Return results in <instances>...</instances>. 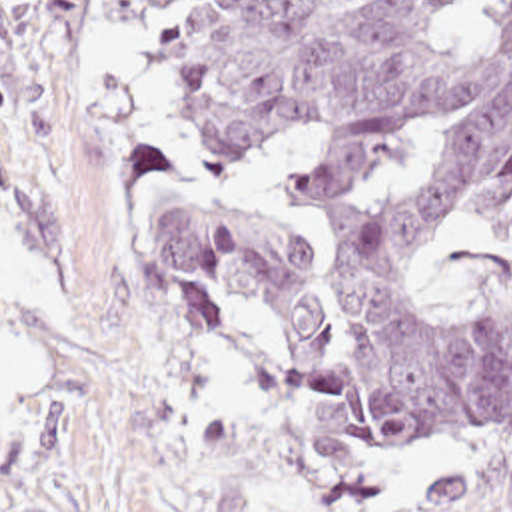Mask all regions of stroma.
<instances>
[{
	"label": "stroma",
	"instance_id": "obj_1",
	"mask_svg": "<svg viewBox=\"0 0 512 512\" xmlns=\"http://www.w3.org/2000/svg\"><path fill=\"white\" fill-rule=\"evenodd\" d=\"M154 30V0H0V342L46 360V390L0 410V512H421L445 469L495 487L512 439L375 447L274 344L164 286L152 240L190 212L328 264L286 200L310 144L204 152L160 104ZM419 276L445 302L512 296V230L449 220Z\"/></svg>",
	"mask_w": 512,
	"mask_h": 512
}]
</instances>
